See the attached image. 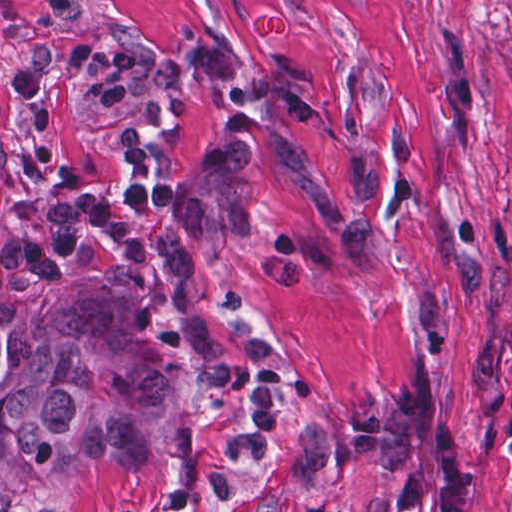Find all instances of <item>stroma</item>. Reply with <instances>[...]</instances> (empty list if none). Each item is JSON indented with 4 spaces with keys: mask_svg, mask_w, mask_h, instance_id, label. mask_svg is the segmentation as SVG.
<instances>
[{
    "mask_svg": "<svg viewBox=\"0 0 512 512\" xmlns=\"http://www.w3.org/2000/svg\"><path fill=\"white\" fill-rule=\"evenodd\" d=\"M512 0H0V259L137 295L176 405L137 461L0 512H402L297 431L424 371L512 512Z\"/></svg>",
    "mask_w": 512,
    "mask_h": 512,
    "instance_id": "obj_1",
    "label": "stroma"
}]
</instances>
